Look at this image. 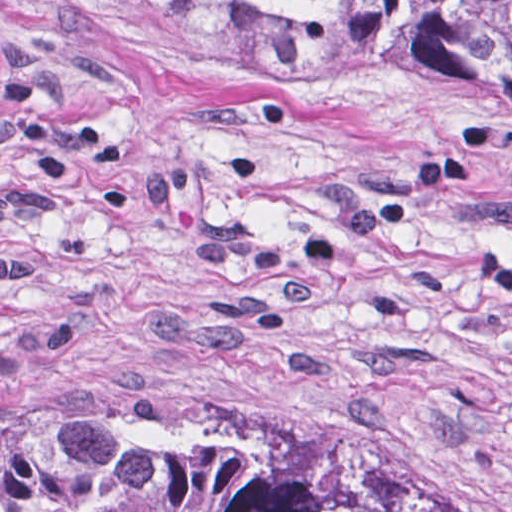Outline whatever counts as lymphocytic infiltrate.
Returning a JSON list of instances; mask_svg holds the SVG:
<instances>
[{
    "mask_svg": "<svg viewBox=\"0 0 512 512\" xmlns=\"http://www.w3.org/2000/svg\"><path fill=\"white\" fill-rule=\"evenodd\" d=\"M475 266L481 277L499 287H512V252L502 249L484 250Z\"/></svg>",
    "mask_w": 512,
    "mask_h": 512,
    "instance_id": "lymphocytic-infiltrate-1",
    "label": "lymphocytic infiltrate"
}]
</instances>
